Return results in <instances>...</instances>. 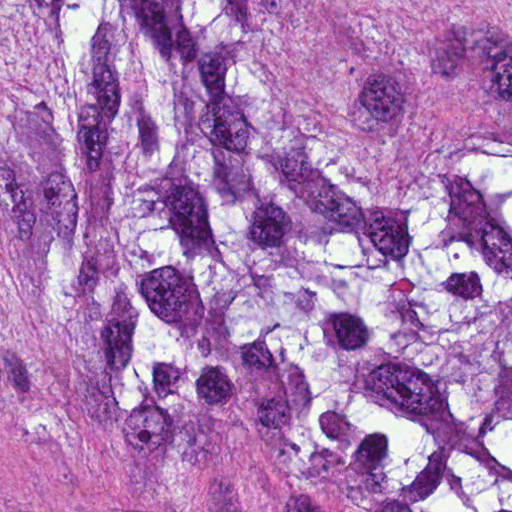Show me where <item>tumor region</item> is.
Masks as SVG:
<instances>
[{
  "label": "tumor region",
  "instance_id": "1",
  "mask_svg": "<svg viewBox=\"0 0 512 512\" xmlns=\"http://www.w3.org/2000/svg\"><path fill=\"white\" fill-rule=\"evenodd\" d=\"M6 377L512 512V1H0Z\"/></svg>",
  "mask_w": 512,
  "mask_h": 512
}]
</instances>
